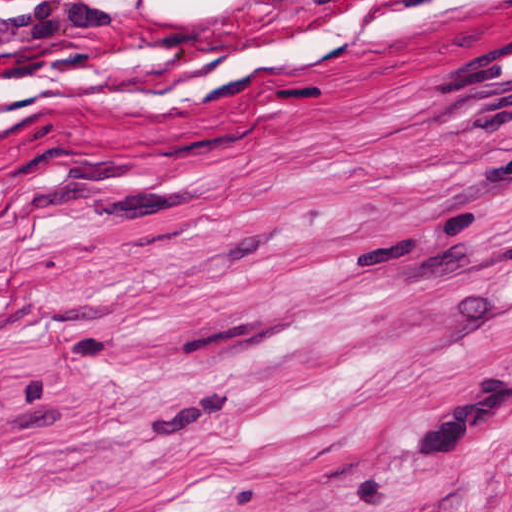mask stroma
Masks as SVG:
<instances>
[{
  "mask_svg": "<svg viewBox=\"0 0 512 512\" xmlns=\"http://www.w3.org/2000/svg\"><path fill=\"white\" fill-rule=\"evenodd\" d=\"M0 512H512V0H0Z\"/></svg>",
  "mask_w": 512,
  "mask_h": 512,
  "instance_id": "obj_1",
  "label": "stroma"
}]
</instances>
